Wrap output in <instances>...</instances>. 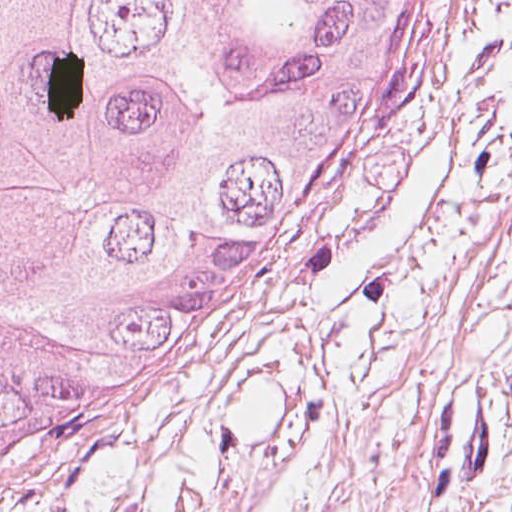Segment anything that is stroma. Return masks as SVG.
Wrapping results in <instances>:
<instances>
[{
  "label": "stroma",
  "mask_w": 512,
  "mask_h": 512,
  "mask_svg": "<svg viewBox=\"0 0 512 512\" xmlns=\"http://www.w3.org/2000/svg\"><path fill=\"white\" fill-rule=\"evenodd\" d=\"M500 0H412L373 152L159 396L0 512H390Z\"/></svg>",
  "instance_id": "obj_1"
}]
</instances>
